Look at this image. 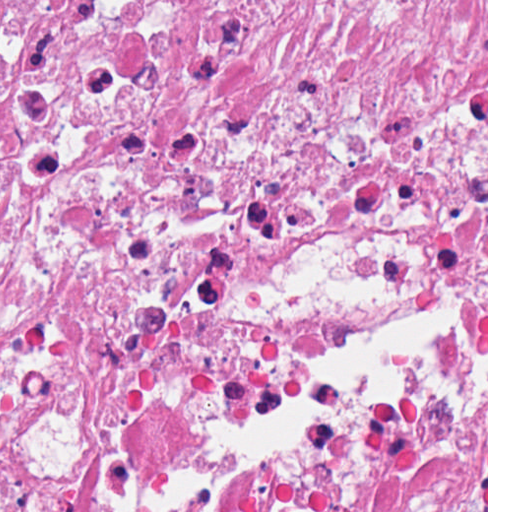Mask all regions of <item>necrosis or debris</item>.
I'll return each mask as SVG.
<instances>
[{"label": "necrosis or debris", "instance_id": "4bbe7bcc", "mask_svg": "<svg viewBox=\"0 0 512 512\" xmlns=\"http://www.w3.org/2000/svg\"><path fill=\"white\" fill-rule=\"evenodd\" d=\"M486 0H0V512H486Z\"/></svg>", "mask_w": 512, "mask_h": 512}]
</instances>
